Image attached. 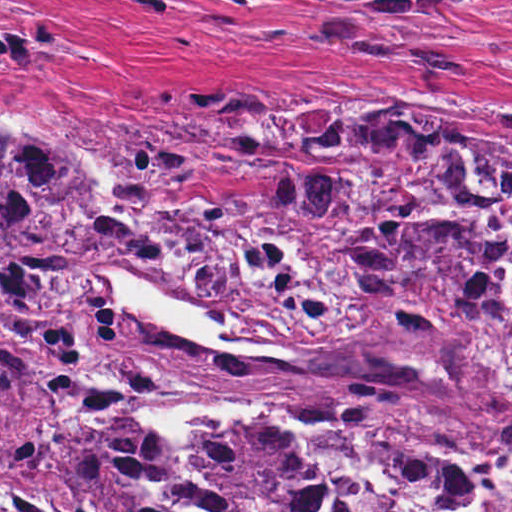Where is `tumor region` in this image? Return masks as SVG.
Wrapping results in <instances>:
<instances>
[{
  "label": "tumor region",
  "mask_w": 512,
  "mask_h": 512,
  "mask_svg": "<svg viewBox=\"0 0 512 512\" xmlns=\"http://www.w3.org/2000/svg\"><path fill=\"white\" fill-rule=\"evenodd\" d=\"M311 1L344 16L456 2L512 7V0ZM0 14L63 19L9 0H0ZM80 53L49 22L0 21V76ZM361 100L366 105L326 90L301 93L233 121L215 99L201 97L130 121L113 154L136 211L108 189L100 157L68 131L0 123V470L99 512L146 508L160 471L149 427L94 411L105 343L128 320L102 285L83 278L113 253L147 247L146 231L145 279L208 310L226 330L288 348L289 356L220 353L132 318L115 356L117 389L142 403L258 406L398 446L512 457V349L477 333L466 296L408 288L361 254L357 334L279 336L237 325L150 252L159 251L155 238L167 216L209 211L289 171H354L355 163L321 155L300 138L302 127L324 116L367 112L412 124ZM407 114L512 193V128ZM166 444L177 458L167 434ZM200 461L215 484L197 489L204 512H338L306 469L271 446L202 437Z\"/></svg>",
  "instance_id": "e687c5a6"
}]
</instances>
